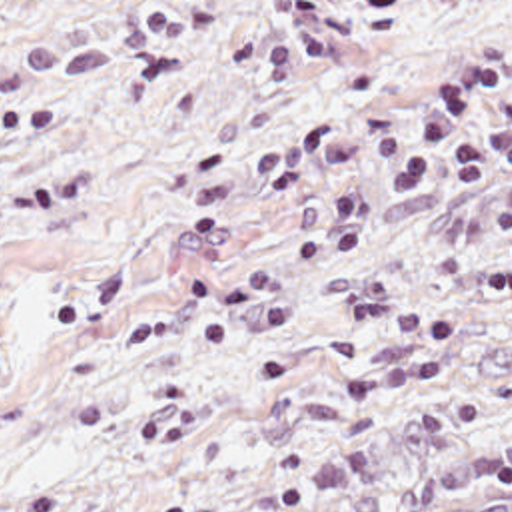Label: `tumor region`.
I'll return each mask as SVG.
<instances>
[{
  "label": "tumor region",
  "mask_w": 512,
  "mask_h": 512,
  "mask_svg": "<svg viewBox=\"0 0 512 512\" xmlns=\"http://www.w3.org/2000/svg\"><path fill=\"white\" fill-rule=\"evenodd\" d=\"M234 512H512V425L438 437L306 503Z\"/></svg>",
  "instance_id": "1"
}]
</instances>
